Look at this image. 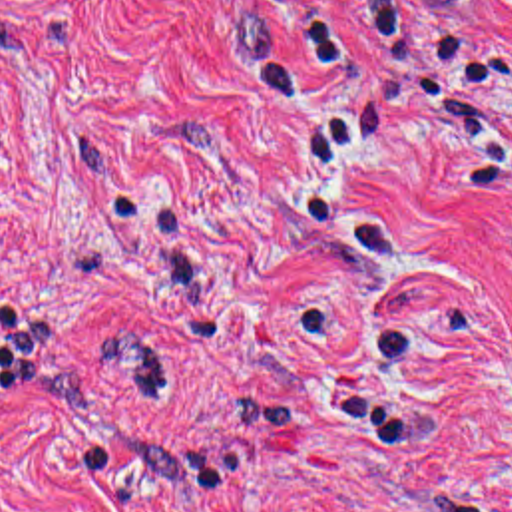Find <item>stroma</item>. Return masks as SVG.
<instances>
[{
	"label": "stroma",
	"instance_id": "stroma-1",
	"mask_svg": "<svg viewBox=\"0 0 512 512\" xmlns=\"http://www.w3.org/2000/svg\"><path fill=\"white\" fill-rule=\"evenodd\" d=\"M0 512H512V0H0Z\"/></svg>",
	"mask_w": 512,
	"mask_h": 512
}]
</instances>
